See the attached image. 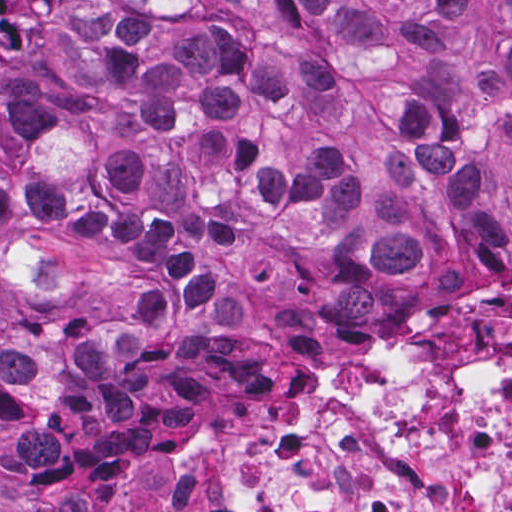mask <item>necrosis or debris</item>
Instances as JSON below:
<instances>
[{
  "mask_svg": "<svg viewBox=\"0 0 512 512\" xmlns=\"http://www.w3.org/2000/svg\"><path fill=\"white\" fill-rule=\"evenodd\" d=\"M164 478L226 512H512V297L362 346Z\"/></svg>",
  "mask_w": 512,
  "mask_h": 512,
  "instance_id": "obj_1",
  "label": "necrosis or debris"
}]
</instances>
